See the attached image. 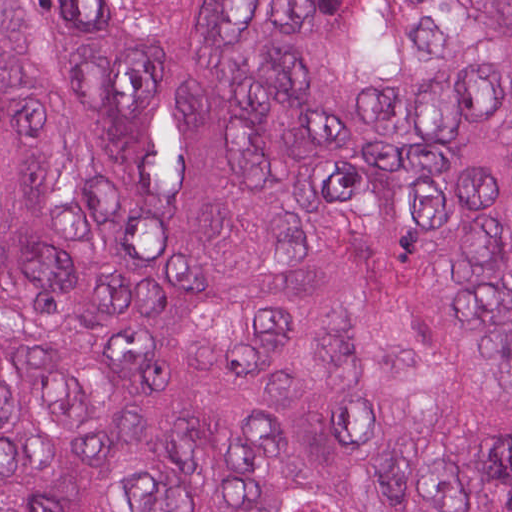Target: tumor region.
Returning <instances> with one entry per match:
<instances>
[{
    "label": "tumor region",
    "mask_w": 512,
    "mask_h": 512,
    "mask_svg": "<svg viewBox=\"0 0 512 512\" xmlns=\"http://www.w3.org/2000/svg\"><path fill=\"white\" fill-rule=\"evenodd\" d=\"M0 512H512V1H0Z\"/></svg>",
    "instance_id": "obj_1"
}]
</instances>
